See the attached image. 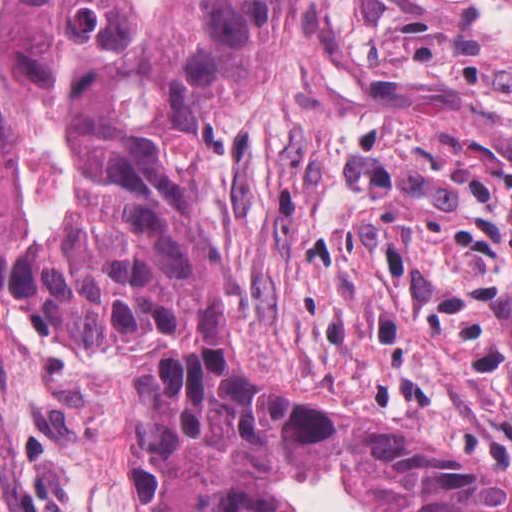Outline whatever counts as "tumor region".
Segmentation results:
<instances>
[{"mask_svg":"<svg viewBox=\"0 0 512 512\" xmlns=\"http://www.w3.org/2000/svg\"><path fill=\"white\" fill-rule=\"evenodd\" d=\"M294 0H0V288L60 353L157 334L138 393L155 512H301L352 466L378 512H512V486L262 372L206 167Z\"/></svg>","mask_w":512,"mask_h":512,"instance_id":"tumor-region-1","label":"tumor region"}]
</instances>
